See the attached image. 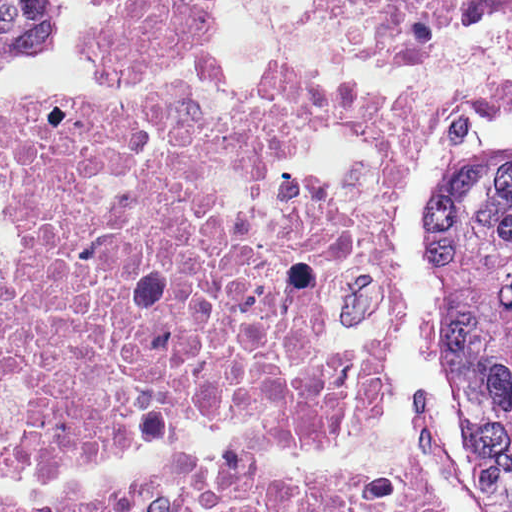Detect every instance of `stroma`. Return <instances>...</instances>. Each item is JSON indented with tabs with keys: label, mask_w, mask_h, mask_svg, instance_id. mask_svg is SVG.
<instances>
[{
	"label": "stroma",
	"mask_w": 512,
	"mask_h": 512,
	"mask_svg": "<svg viewBox=\"0 0 512 512\" xmlns=\"http://www.w3.org/2000/svg\"><path fill=\"white\" fill-rule=\"evenodd\" d=\"M107 18L108 0H57L52 46L0 64V92L54 88L70 104L103 112L145 108L185 92L221 112L259 104L289 76H330L382 100L462 88L452 128L417 155L393 213V277L405 334L393 353L381 432L396 441L401 423L412 436L440 512H506L496 462L468 454L448 420L425 282V198L441 152L460 141L512 142V17L475 22L402 53H378L339 45L306 0H224L206 40L155 79H106L92 73V59L88 69L72 57ZM16 235L1 219L0 171V250Z\"/></svg>",
	"instance_id": "stroma-1"
}]
</instances>
